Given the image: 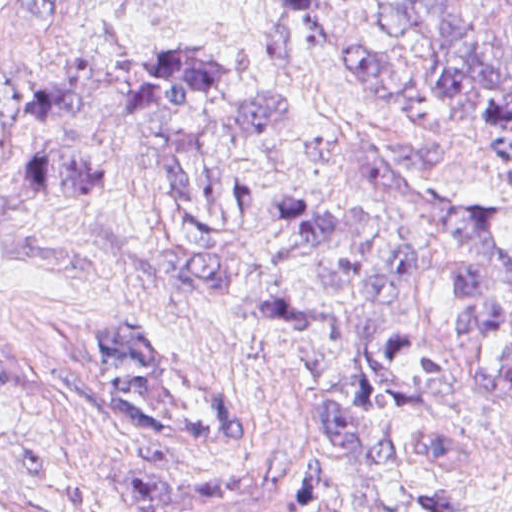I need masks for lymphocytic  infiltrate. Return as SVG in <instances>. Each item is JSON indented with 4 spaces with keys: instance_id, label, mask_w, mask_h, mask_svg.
I'll use <instances>...</instances> for the list:
<instances>
[{
    "instance_id": "1",
    "label": "lymphocytic infiltrate",
    "mask_w": 512,
    "mask_h": 512,
    "mask_svg": "<svg viewBox=\"0 0 512 512\" xmlns=\"http://www.w3.org/2000/svg\"><path fill=\"white\" fill-rule=\"evenodd\" d=\"M426 512H474V504L452 483L430 482Z\"/></svg>"
}]
</instances>
